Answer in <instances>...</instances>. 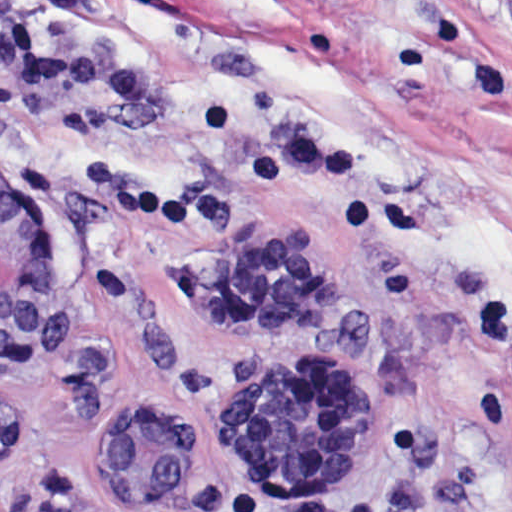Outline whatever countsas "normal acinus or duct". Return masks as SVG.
Instances as JSON below:
<instances>
[{
	"label": "normal acinus or duct",
	"instance_id": "1",
	"mask_svg": "<svg viewBox=\"0 0 512 512\" xmlns=\"http://www.w3.org/2000/svg\"><path fill=\"white\" fill-rule=\"evenodd\" d=\"M52 290L45 237L0 176V358L29 363L45 330Z\"/></svg>",
	"mask_w": 512,
	"mask_h": 512
}]
</instances>
